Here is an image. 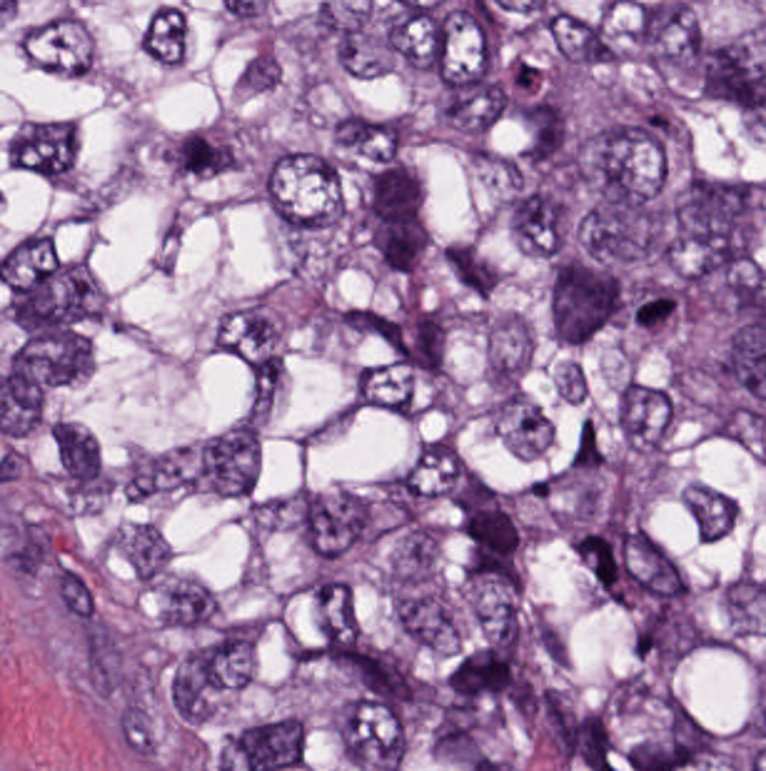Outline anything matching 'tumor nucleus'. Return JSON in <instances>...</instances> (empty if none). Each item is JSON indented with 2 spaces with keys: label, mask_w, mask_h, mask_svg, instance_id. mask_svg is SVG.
<instances>
[{
  "label": "tumor nucleus",
  "mask_w": 766,
  "mask_h": 771,
  "mask_svg": "<svg viewBox=\"0 0 766 771\" xmlns=\"http://www.w3.org/2000/svg\"><path fill=\"white\" fill-rule=\"evenodd\" d=\"M766 182L758 176L680 166L655 183V241L670 279L713 289L751 259Z\"/></svg>",
  "instance_id": "obj_1"
},
{
  "label": "tumor nucleus",
  "mask_w": 766,
  "mask_h": 771,
  "mask_svg": "<svg viewBox=\"0 0 766 771\" xmlns=\"http://www.w3.org/2000/svg\"><path fill=\"white\" fill-rule=\"evenodd\" d=\"M570 202H676V121H570Z\"/></svg>",
  "instance_id": "obj_2"
},
{
  "label": "tumor nucleus",
  "mask_w": 766,
  "mask_h": 771,
  "mask_svg": "<svg viewBox=\"0 0 766 771\" xmlns=\"http://www.w3.org/2000/svg\"><path fill=\"white\" fill-rule=\"evenodd\" d=\"M378 580L389 622L403 639L420 649L464 644L469 609L431 533L395 530Z\"/></svg>",
  "instance_id": "obj_3"
},
{
  "label": "tumor nucleus",
  "mask_w": 766,
  "mask_h": 771,
  "mask_svg": "<svg viewBox=\"0 0 766 771\" xmlns=\"http://www.w3.org/2000/svg\"><path fill=\"white\" fill-rule=\"evenodd\" d=\"M163 721H259V640H163Z\"/></svg>",
  "instance_id": "obj_4"
},
{
  "label": "tumor nucleus",
  "mask_w": 766,
  "mask_h": 771,
  "mask_svg": "<svg viewBox=\"0 0 766 771\" xmlns=\"http://www.w3.org/2000/svg\"><path fill=\"white\" fill-rule=\"evenodd\" d=\"M608 771H683V677H608Z\"/></svg>",
  "instance_id": "obj_5"
},
{
  "label": "tumor nucleus",
  "mask_w": 766,
  "mask_h": 771,
  "mask_svg": "<svg viewBox=\"0 0 766 771\" xmlns=\"http://www.w3.org/2000/svg\"><path fill=\"white\" fill-rule=\"evenodd\" d=\"M14 319H109V253H14Z\"/></svg>",
  "instance_id": "obj_6"
},
{
  "label": "tumor nucleus",
  "mask_w": 766,
  "mask_h": 771,
  "mask_svg": "<svg viewBox=\"0 0 766 771\" xmlns=\"http://www.w3.org/2000/svg\"><path fill=\"white\" fill-rule=\"evenodd\" d=\"M286 337L278 297L256 291L220 309L208 328V347L258 384H277Z\"/></svg>",
  "instance_id": "obj_7"
},
{
  "label": "tumor nucleus",
  "mask_w": 766,
  "mask_h": 771,
  "mask_svg": "<svg viewBox=\"0 0 766 771\" xmlns=\"http://www.w3.org/2000/svg\"><path fill=\"white\" fill-rule=\"evenodd\" d=\"M296 549H371V478H296Z\"/></svg>",
  "instance_id": "obj_8"
},
{
  "label": "tumor nucleus",
  "mask_w": 766,
  "mask_h": 771,
  "mask_svg": "<svg viewBox=\"0 0 766 771\" xmlns=\"http://www.w3.org/2000/svg\"><path fill=\"white\" fill-rule=\"evenodd\" d=\"M623 601H693V525H623Z\"/></svg>",
  "instance_id": "obj_9"
},
{
  "label": "tumor nucleus",
  "mask_w": 766,
  "mask_h": 771,
  "mask_svg": "<svg viewBox=\"0 0 766 771\" xmlns=\"http://www.w3.org/2000/svg\"><path fill=\"white\" fill-rule=\"evenodd\" d=\"M676 416V385L624 374L610 407V426L625 469H661Z\"/></svg>",
  "instance_id": "obj_10"
},
{
  "label": "tumor nucleus",
  "mask_w": 766,
  "mask_h": 771,
  "mask_svg": "<svg viewBox=\"0 0 766 771\" xmlns=\"http://www.w3.org/2000/svg\"><path fill=\"white\" fill-rule=\"evenodd\" d=\"M261 434L262 415L246 405L196 438L188 491L242 501L257 481Z\"/></svg>",
  "instance_id": "obj_11"
},
{
  "label": "tumor nucleus",
  "mask_w": 766,
  "mask_h": 771,
  "mask_svg": "<svg viewBox=\"0 0 766 771\" xmlns=\"http://www.w3.org/2000/svg\"><path fill=\"white\" fill-rule=\"evenodd\" d=\"M550 337H621V266H550Z\"/></svg>",
  "instance_id": "obj_12"
},
{
  "label": "tumor nucleus",
  "mask_w": 766,
  "mask_h": 771,
  "mask_svg": "<svg viewBox=\"0 0 766 771\" xmlns=\"http://www.w3.org/2000/svg\"><path fill=\"white\" fill-rule=\"evenodd\" d=\"M263 219H339V153H263Z\"/></svg>",
  "instance_id": "obj_13"
},
{
  "label": "tumor nucleus",
  "mask_w": 766,
  "mask_h": 771,
  "mask_svg": "<svg viewBox=\"0 0 766 771\" xmlns=\"http://www.w3.org/2000/svg\"><path fill=\"white\" fill-rule=\"evenodd\" d=\"M460 219H521V138H460Z\"/></svg>",
  "instance_id": "obj_14"
},
{
  "label": "tumor nucleus",
  "mask_w": 766,
  "mask_h": 771,
  "mask_svg": "<svg viewBox=\"0 0 766 771\" xmlns=\"http://www.w3.org/2000/svg\"><path fill=\"white\" fill-rule=\"evenodd\" d=\"M343 771H409V697H343Z\"/></svg>",
  "instance_id": "obj_15"
},
{
  "label": "tumor nucleus",
  "mask_w": 766,
  "mask_h": 771,
  "mask_svg": "<svg viewBox=\"0 0 766 771\" xmlns=\"http://www.w3.org/2000/svg\"><path fill=\"white\" fill-rule=\"evenodd\" d=\"M9 167L48 187H74L79 144L72 118L39 113L21 118L1 143Z\"/></svg>",
  "instance_id": "obj_16"
},
{
  "label": "tumor nucleus",
  "mask_w": 766,
  "mask_h": 771,
  "mask_svg": "<svg viewBox=\"0 0 766 771\" xmlns=\"http://www.w3.org/2000/svg\"><path fill=\"white\" fill-rule=\"evenodd\" d=\"M435 84H496V9H435Z\"/></svg>",
  "instance_id": "obj_17"
},
{
  "label": "tumor nucleus",
  "mask_w": 766,
  "mask_h": 771,
  "mask_svg": "<svg viewBox=\"0 0 766 771\" xmlns=\"http://www.w3.org/2000/svg\"><path fill=\"white\" fill-rule=\"evenodd\" d=\"M46 475L63 509H89L109 495V472L101 452L89 428L77 420L51 418Z\"/></svg>",
  "instance_id": "obj_18"
},
{
  "label": "tumor nucleus",
  "mask_w": 766,
  "mask_h": 771,
  "mask_svg": "<svg viewBox=\"0 0 766 771\" xmlns=\"http://www.w3.org/2000/svg\"><path fill=\"white\" fill-rule=\"evenodd\" d=\"M333 162H419V111H333Z\"/></svg>",
  "instance_id": "obj_19"
},
{
  "label": "tumor nucleus",
  "mask_w": 766,
  "mask_h": 771,
  "mask_svg": "<svg viewBox=\"0 0 766 771\" xmlns=\"http://www.w3.org/2000/svg\"><path fill=\"white\" fill-rule=\"evenodd\" d=\"M395 499H461V433H395Z\"/></svg>",
  "instance_id": "obj_20"
},
{
  "label": "tumor nucleus",
  "mask_w": 766,
  "mask_h": 771,
  "mask_svg": "<svg viewBox=\"0 0 766 771\" xmlns=\"http://www.w3.org/2000/svg\"><path fill=\"white\" fill-rule=\"evenodd\" d=\"M151 626H217V560H151Z\"/></svg>",
  "instance_id": "obj_21"
},
{
  "label": "tumor nucleus",
  "mask_w": 766,
  "mask_h": 771,
  "mask_svg": "<svg viewBox=\"0 0 766 771\" xmlns=\"http://www.w3.org/2000/svg\"><path fill=\"white\" fill-rule=\"evenodd\" d=\"M508 249H579V188H508Z\"/></svg>",
  "instance_id": "obj_22"
},
{
  "label": "tumor nucleus",
  "mask_w": 766,
  "mask_h": 771,
  "mask_svg": "<svg viewBox=\"0 0 766 771\" xmlns=\"http://www.w3.org/2000/svg\"><path fill=\"white\" fill-rule=\"evenodd\" d=\"M483 389L485 416L510 451L539 456L554 441L549 405L521 380L488 370Z\"/></svg>",
  "instance_id": "obj_23"
},
{
  "label": "tumor nucleus",
  "mask_w": 766,
  "mask_h": 771,
  "mask_svg": "<svg viewBox=\"0 0 766 771\" xmlns=\"http://www.w3.org/2000/svg\"><path fill=\"white\" fill-rule=\"evenodd\" d=\"M585 254H661V198H585Z\"/></svg>",
  "instance_id": "obj_24"
},
{
  "label": "tumor nucleus",
  "mask_w": 766,
  "mask_h": 771,
  "mask_svg": "<svg viewBox=\"0 0 766 771\" xmlns=\"http://www.w3.org/2000/svg\"><path fill=\"white\" fill-rule=\"evenodd\" d=\"M158 152L173 177L207 179L247 167L249 142L232 123L211 121L168 136Z\"/></svg>",
  "instance_id": "obj_25"
},
{
  "label": "tumor nucleus",
  "mask_w": 766,
  "mask_h": 771,
  "mask_svg": "<svg viewBox=\"0 0 766 771\" xmlns=\"http://www.w3.org/2000/svg\"><path fill=\"white\" fill-rule=\"evenodd\" d=\"M370 262H441V206H370Z\"/></svg>",
  "instance_id": "obj_26"
},
{
  "label": "tumor nucleus",
  "mask_w": 766,
  "mask_h": 771,
  "mask_svg": "<svg viewBox=\"0 0 766 771\" xmlns=\"http://www.w3.org/2000/svg\"><path fill=\"white\" fill-rule=\"evenodd\" d=\"M9 364H94V318H9Z\"/></svg>",
  "instance_id": "obj_27"
},
{
  "label": "tumor nucleus",
  "mask_w": 766,
  "mask_h": 771,
  "mask_svg": "<svg viewBox=\"0 0 766 771\" xmlns=\"http://www.w3.org/2000/svg\"><path fill=\"white\" fill-rule=\"evenodd\" d=\"M453 556H529V505H453Z\"/></svg>",
  "instance_id": "obj_28"
},
{
  "label": "tumor nucleus",
  "mask_w": 766,
  "mask_h": 771,
  "mask_svg": "<svg viewBox=\"0 0 766 771\" xmlns=\"http://www.w3.org/2000/svg\"><path fill=\"white\" fill-rule=\"evenodd\" d=\"M448 696H514V640H448Z\"/></svg>",
  "instance_id": "obj_29"
},
{
  "label": "tumor nucleus",
  "mask_w": 766,
  "mask_h": 771,
  "mask_svg": "<svg viewBox=\"0 0 766 771\" xmlns=\"http://www.w3.org/2000/svg\"><path fill=\"white\" fill-rule=\"evenodd\" d=\"M113 491L128 501H149L177 491L189 479V443L136 448L113 465Z\"/></svg>",
  "instance_id": "obj_30"
},
{
  "label": "tumor nucleus",
  "mask_w": 766,
  "mask_h": 771,
  "mask_svg": "<svg viewBox=\"0 0 766 771\" xmlns=\"http://www.w3.org/2000/svg\"><path fill=\"white\" fill-rule=\"evenodd\" d=\"M24 54L61 77H84L94 69V48L74 16H36L26 24Z\"/></svg>",
  "instance_id": "obj_31"
},
{
  "label": "tumor nucleus",
  "mask_w": 766,
  "mask_h": 771,
  "mask_svg": "<svg viewBox=\"0 0 766 771\" xmlns=\"http://www.w3.org/2000/svg\"><path fill=\"white\" fill-rule=\"evenodd\" d=\"M308 639H364V578H308Z\"/></svg>",
  "instance_id": "obj_32"
},
{
  "label": "tumor nucleus",
  "mask_w": 766,
  "mask_h": 771,
  "mask_svg": "<svg viewBox=\"0 0 766 771\" xmlns=\"http://www.w3.org/2000/svg\"><path fill=\"white\" fill-rule=\"evenodd\" d=\"M468 636H519V570H468Z\"/></svg>",
  "instance_id": "obj_33"
},
{
  "label": "tumor nucleus",
  "mask_w": 766,
  "mask_h": 771,
  "mask_svg": "<svg viewBox=\"0 0 766 771\" xmlns=\"http://www.w3.org/2000/svg\"><path fill=\"white\" fill-rule=\"evenodd\" d=\"M331 77H396V26H331Z\"/></svg>",
  "instance_id": "obj_34"
},
{
  "label": "tumor nucleus",
  "mask_w": 766,
  "mask_h": 771,
  "mask_svg": "<svg viewBox=\"0 0 766 771\" xmlns=\"http://www.w3.org/2000/svg\"><path fill=\"white\" fill-rule=\"evenodd\" d=\"M445 134H506V83H445Z\"/></svg>",
  "instance_id": "obj_35"
},
{
  "label": "tumor nucleus",
  "mask_w": 766,
  "mask_h": 771,
  "mask_svg": "<svg viewBox=\"0 0 766 771\" xmlns=\"http://www.w3.org/2000/svg\"><path fill=\"white\" fill-rule=\"evenodd\" d=\"M353 399H419V353H353Z\"/></svg>",
  "instance_id": "obj_36"
},
{
  "label": "tumor nucleus",
  "mask_w": 766,
  "mask_h": 771,
  "mask_svg": "<svg viewBox=\"0 0 766 771\" xmlns=\"http://www.w3.org/2000/svg\"><path fill=\"white\" fill-rule=\"evenodd\" d=\"M480 337L485 366L521 379L534 345L530 319L516 311L490 308Z\"/></svg>",
  "instance_id": "obj_37"
},
{
  "label": "tumor nucleus",
  "mask_w": 766,
  "mask_h": 771,
  "mask_svg": "<svg viewBox=\"0 0 766 771\" xmlns=\"http://www.w3.org/2000/svg\"><path fill=\"white\" fill-rule=\"evenodd\" d=\"M113 549L132 576L162 581L172 566L167 538L152 520L128 518L112 526Z\"/></svg>",
  "instance_id": "obj_38"
},
{
  "label": "tumor nucleus",
  "mask_w": 766,
  "mask_h": 771,
  "mask_svg": "<svg viewBox=\"0 0 766 771\" xmlns=\"http://www.w3.org/2000/svg\"><path fill=\"white\" fill-rule=\"evenodd\" d=\"M520 157H571V101H520Z\"/></svg>",
  "instance_id": "obj_39"
},
{
  "label": "tumor nucleus",
  "mask_w": 766,
  "mask_h": 771,
  "mask_svg": "<svg viewBox=\"0 0 766 771\" xmlns=\"http://www.w3.org/2000/svg\"><path fill=\"white\" fill-rule=\"evenodd\" d=\"M545 401H606V355H545Z\"/></svg>",
  "instance_id": "obj_40"
},
{
  "label": "tumor nucleus",
  "mask_w": 766,
  "mask_h": 771,
  "mask_svg": "<svg viewBox=\"0 0 766 771\" xmlns=\"http://www.w3.org/2000/svg\"><path fill=\"white\" fill-rule=\"evenodd\" d=\"M440 264L458 292L485 298L495 286L499 266L471 236L440 246Z\"/></svg>",
  "instance_id": "obj_41"
},
{
  "label": "tumor nucleus",
  "mask_w": 766,
  "mask_h": 771,
  "mask_svg": "<svg viewBox=\"0 0 766 771\" xmlns=\"http://www.w3.org/2000/svg\"><path fill=\"white\" fill-rule=\"evenodd\" d=\"M390 67H436V11H390Z\"/></svg>",
  "instance_id": "obj_42"
},
{
  "label": "tumor nucleus",
  "mask_w": 766,
  "mask_h": 771,
  "mask_svg": "<svg viewBox=\"0 0 766 771\" xmlns=\"http://www.w3.org/2000/svg\"><path fill=\"white\" fill-rule=\"evenodd\" d=\"M680 502L697 539L718 541L731 531L736 503L726 490L692 480L681 486Z\"/></svg>",
  "instance_id": "obj_43"
},
{
  "label": "tumor nucleus",
  "mask_w": 766,
  "mask_h": 771,
  "mask_svg": "<svg viewBox=\"0 0 766 771\" xmlns=\"http://www.w3.org/2000/svg\"><path fill=\"white\" fill-rule=\"evenodd\" d=\"M136 33L153 62L177 64L184 54L187 21L169 1H156L143 16Z\"/></svg>",
  "instance_id": "obj_44"
},
{
  "label": "tumor nucleus",
  "mask_w": 766,
  "mask_h": 771,
  "mask_svg": "<svg viewBox=\"0 0 766 771\" xmlns=\"http://www.w3.org/2000/svg\"><path fill=\"white\" fill-rule=\"evenodd\" d=\"M365 207H426V171H365Z\"/></svg>",
  "instance_id": "obj_45"
},
{
  "label": "tumor nucleus",
  "mask_w": 766,
  "mask_h": 771,
  "mask_svg": "<svg viewBox=\"0 0 766 771\" xmlns=\"http://www.w3.org/2000/svg\"><path fill=\"white\" fill-rule=\"evenodd\" d=\"M638 334H683V288H638Z\"/></svg>",
  "instance_id": "obj_46"
},
{
  "label": "tumor nucleus",
  "mask_w": 766,
  "mask_h": 771,
  "mask_svg": "<svg viewBox=\"0 0 766 771\" xmlns=\"http://www.w3.org/2000/svg\"><path fill=\"white\" fill-rule=\"evenodd\" d=\"M565 469H596V413H565Z\"/></svg>",
  "instance_id": "obj_47"
}]
</instances>
